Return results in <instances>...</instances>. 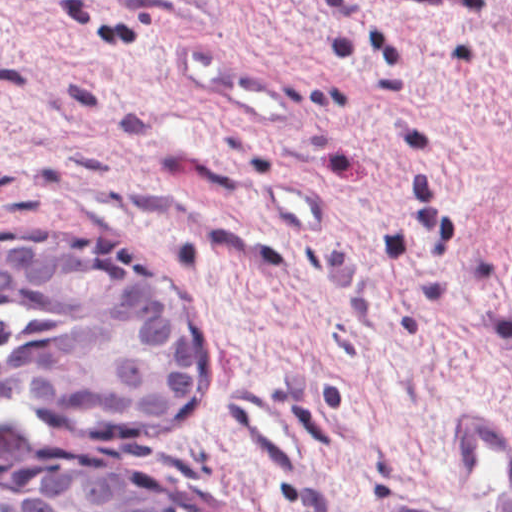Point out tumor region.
Masks as SVG:
<instances>
[{"instance_id":"1","label":"tumor region","mask_w":512,"mask_h":512,"mask_svg":"<svg viewBox=\"0 0 512 512\" xmlns=\"http://www.w3.org/2000/svg\"><path fill=\"white\" fill-rule=\"evenodd\" d=\"M7 308L49 324L10 358L8 383L19 398L145 423L210 397V343L200 317L161 281L96 245L0 240V311Z\"/></svg>"}]
</instances>
